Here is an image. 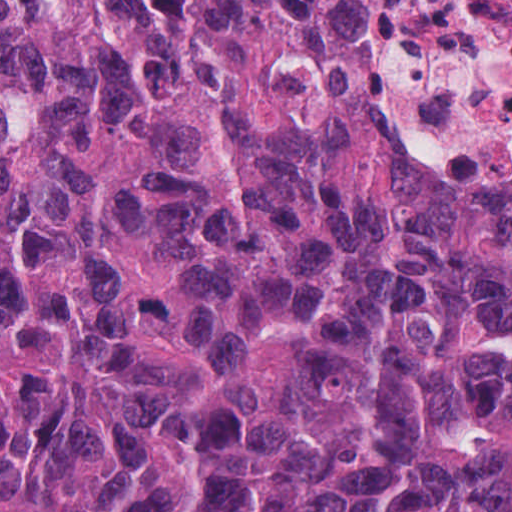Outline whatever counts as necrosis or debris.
Masks as SVG:
<instances>
[{"mask_svg": "<svg viewBox=\"0 0 512 512\" xmlns=\"http://www.w3.org/2000/svg\"><path fill=\"white\" fill-rule=\"evenodd\" d=\"M383 126L410 156L512 184V0H396Z\"/></svg>", "mask_w": 512, "mask_h": 512, "instance_id": "necrosis-or-debris-1", "label": "necrosis or debris"}]
</instances>
